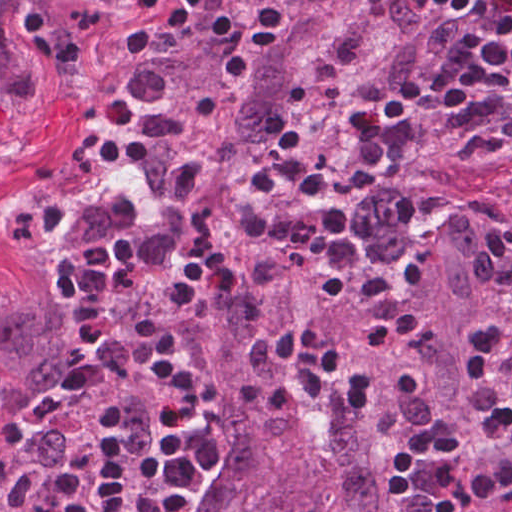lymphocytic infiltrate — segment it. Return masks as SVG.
Returning <instances> with one entry per match:
<instances>
[{
  "label": "lymphocytic infiltrate",
  "mask_w": 512,
  "mask_h": 512,
  "mask_svg": "<svg viewBox=\"0 0 512 512\" xmlns=\"http://www.w3.org/2000/svg\"><path fill=\"white\" fill-rule=\"evenodd\" d=\"M175 0H156L138 22L163 37ZM299 131L287 127L250 174L244 187V227L257 243L292 248L323 265L319 289L343 297L349 275L357 294L394 290V282L365 266L347 227L348 215L327 205L299 216H273L263 207L272 183L312 200L329 187L327 169L296 157ZM380 186L389 216L402 228L456 203L484 182L512 187V0H426L397 127L378 158ZM235 250L220 216L204 221L164 282L151 316L152 368L171 404L156 442L154 467L159 512H186L208 464L201 436L179 430L198 412L200 385L175 348L176 319L187 303L231 281ZM55 279L70 314L69 352L61 388L97 386L111 329L105 301L118 291L143 289L144 264L137 249L121 242L66 252ZM487 330L466 373L456 414L487 459L465 471L455 430L435 415L411 430L388 466L390 498L412 499L422 476L436 489L426 512H479L512 492V224L501 230V251ZM254 367L293 363L295 379L253 378L236 398L288 412L299 397L363 413L369 401L366 375L341 391L334 387L345 361L323 348L315 326L298 323L256 340ZM129 448L122 427L105 430L87 461L91 488L79 512H119Z\"/></svg>",
  "instance_id": "obj_1"
}]
</instances>
